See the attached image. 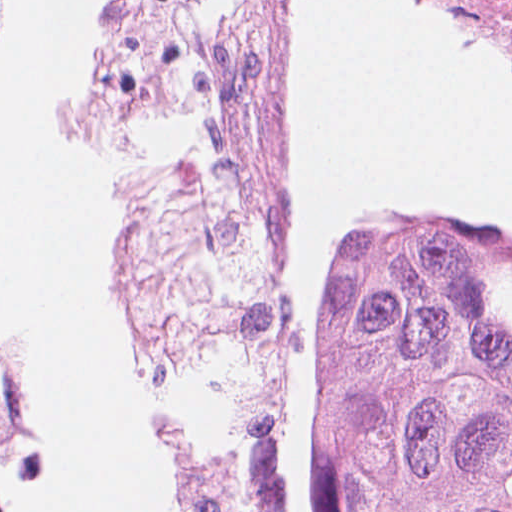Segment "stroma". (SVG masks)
Segmentation results:
<instances>
[{
    "label": "stroma",
    "instance_id": "stroma-1",
    "mask_svg": "<svg viewBox=\"0 0 512 512\" xmlns=\"http://www.w3.org/2000/svg\"><path fill=\"white\" fill-rule=\"evenodd\" d=\"M445 2L512 51V0ZM309 12L310 0H304L296 57ZM171 44L172 0L114 1L98 58V135L115 167L119 187L158 163L164 136V92ZM264 262L279 314L267 470L279 495L280 512H289L286 483L272 437L281 395L299 359L301 321L303 342L301 295L293 275V179L289 159L275 240ZM105 279L116 303L112 221L105 249ZM314 505L316 512H337V500L320 477Z\"/></svg>",
    "mask_w": 512,
    "mask_h": 512
}]
</instances>
